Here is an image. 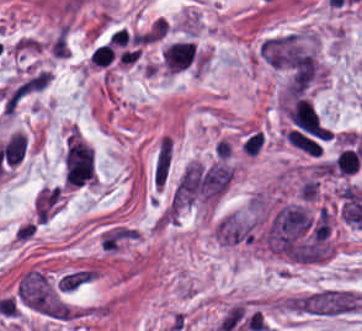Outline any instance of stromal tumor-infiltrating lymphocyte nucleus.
<instances>
[{
    "label": "stromal tumor-infiltrating lymphocyte nucleus",
    "mask_w": 362,
    "mask_h": 331,
    "mask_svg": "<svg viewBox=\"0 0 362 331\" xmlns=\"http://www.w3.org/2000/svg\"><path fill=\"white\" fill-rule=\"evenodd\" d=\"M66 186H79V185H74V184H67Z\"/></svg>",
    "instance_id": "2"
},
{
    "label": "stromal tumor-infiltrating lymphocyte nucleus",
    "mask_w": 362,
    "mask_h": 331,
    "mask_svg": "<svg viewBox=\"0 0 362 331\" xmlns=\"http://www.w3.org/2000/svg\"><path fill=\"white\" fill-rule=\"evenodd\" d=\"M199 51L188 39H174L161 50V66L166 72L179 73L196 63Z\"/></svg>",
    "instance_id": "1"
}]
</instances>
